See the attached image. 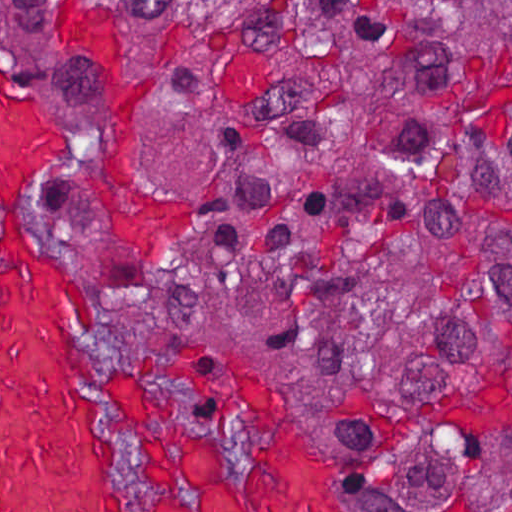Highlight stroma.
I'll return each instance as SVG.
<instances>
[{
	"label": "stroma",
	"mask_w": 512,
	"mask_h": 512,
	"mask_svg": "<svg viewBox=\"0 0 512 512\" xmlns=\"http://www.w3.org/2000/svg\"><path fill=\"white\" fill-rule=\"evenodd\" d=\"M0 1H512V0H0ZM0 65L52 110L88 161L118 190L155 202L170 218L165 238L106 218L79 178L60 165L40 215V234L80 271L98 298L96 319L79 311V331L106 398L113 453L137 504L150 464L115 378L134 380L171 429L213 426L223 464L237 477L253 445L236 409L240 374L261 371L332 471L350 512H405L368 474L362 455L314 402L294 366L238 324L213 320L163 298H130L149 281L188 269L194 252L191 177L170 169L114 165L78 89L25 32L0 22Z\"/></svg>",
	"instance_id": "1"
}]
</instances>
